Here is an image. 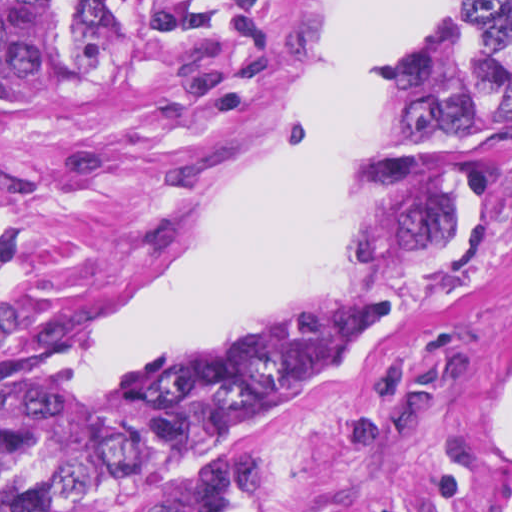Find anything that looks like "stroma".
<instances>
[{"instance_id":"35a3bbf8","label":"stroma","mask_w":512,"mask_h":512,"mask_svg":"<svg viewBox=\"0 0 512 512\" xmlns=\"http://www.w3.org/2000/svg\"><path fill=\"white\" fill-rule=\"evenodd\" d=\"M199 1L213 43L1 121L0 0V512L1 303L45 292L74 341L166 261L235 166L288 122L298 56L337 2ZM377 133L378 119L359 172ZM511 403L512 186L462 278L267 422L228 477L256 512H503Z\"/></svg>"}]
</instances>
